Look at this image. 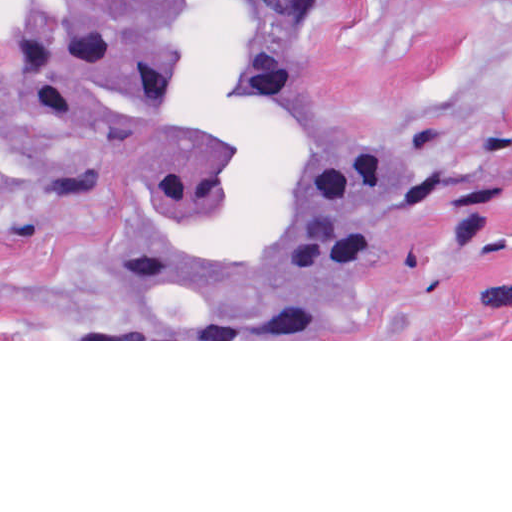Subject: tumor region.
<instances>
[{
  "label": "tumor region",
  "mask_w": 512,
  "mask_h": 512,
  "mask_svg": "<svg viewBox=\"0 0 512 512\" xmlns=\"http://www.w3.org/2000/svg\"><path fill=\"white\" fill-rule=\"evenodd\" d=\"M314 5L6 0L0 146L88 199L155 300L196 289L266 315L389 241L427 195L410 145L302 106Z\"/></svg>",
  "instance_id": "tumor-region-1"
}]
</instances>
